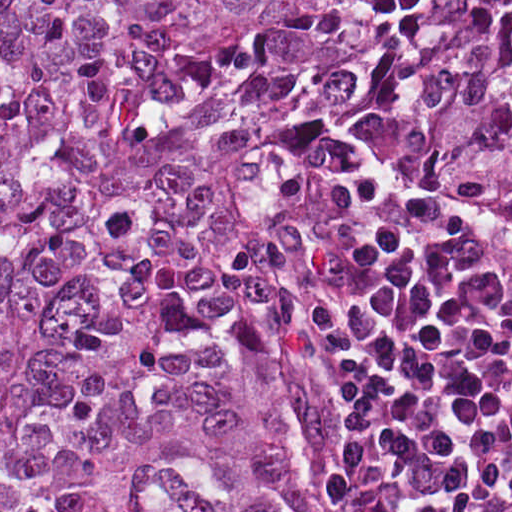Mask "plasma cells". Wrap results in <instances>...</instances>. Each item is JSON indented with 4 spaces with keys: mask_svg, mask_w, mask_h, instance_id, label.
<instances>
[{
    "mask_svg": "<svg viewBox=\"0 0 512 512\" xmlns=\"http://www.w3.org/2000/svg\"><path fill=\"white\" fill-rule=\"evenodd\" d=\"M300 326L362 442L354 512H512V243L353 166Z\"/></svg>",
    "mask_w": 512,
    "mask_h": 512,
    "instance_id": "9512152a",
    "label": "plasma cells"
}]
</instances>
